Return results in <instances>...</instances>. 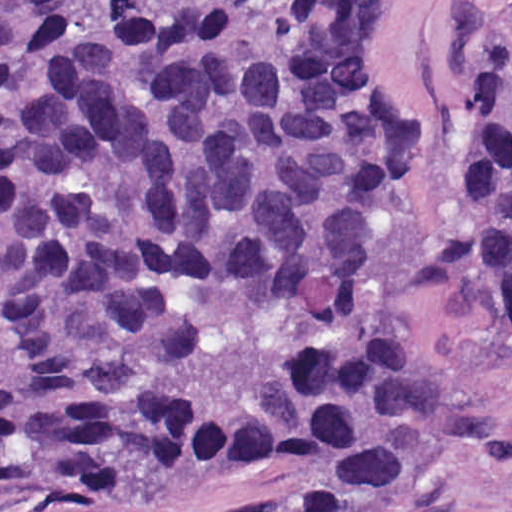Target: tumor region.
<instances>
[{"label":"tumor region","instance_id":"e687c5a6","mask_svg":"<svg viewBox=\"0 0 512 512\" xmlns=\"http://www.w3.org/2000/svg\"><path fill=\"white\" fill-rule=\"evenodd\" d=\"M383 2L0 0V493L208 472L350 512L468 440L366 303L425 145ZM462 265L512 316V38Z\"/></svg>","mask_w":512,"mask_h":512}]
</instances>
